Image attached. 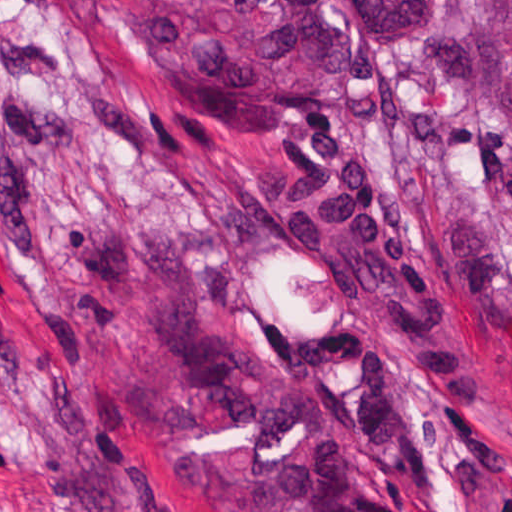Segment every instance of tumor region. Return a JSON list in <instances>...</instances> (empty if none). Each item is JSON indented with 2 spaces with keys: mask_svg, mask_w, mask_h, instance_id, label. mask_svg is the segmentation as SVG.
<instances>
[{
  "mask_svg": "<svg viewBox=\"0 0 512 512\" xmlns=\"http://www.w3.org/2000/svg\"><path fill=\"white\" fill-rule=\"evenodd\" d=\"M188 87L223 109H318L347 87L349 37L428 41L432 137L486 179L457 282L512 339V0H109Z\"/></svg>",
  "mask_w": 512,
  "mask_h": 512,
  "instance_id": "1",
  "label": "tumor region"
}]
</instances>
